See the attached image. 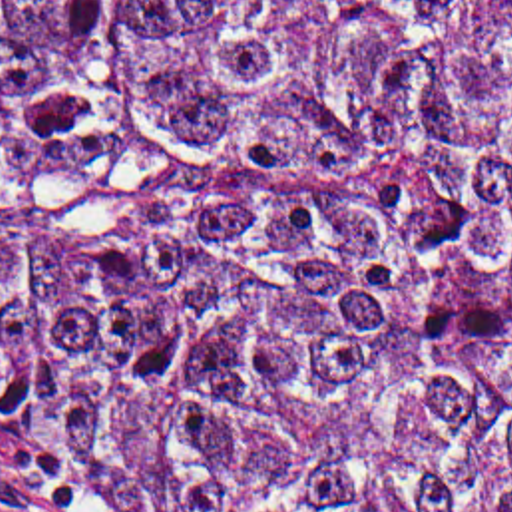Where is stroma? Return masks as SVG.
Returning a JSON list of instances; mask_svg holds the SVG:
<instances>
[{
	"label": "stroma",
	"mask_w": 512,
	"mask_h": 512,
	"mask_svg": "<svg viewBox=\"0 0 512 512\" xmlns=\"http://www.w3.org/2000/svg\"><path fill=\"white\" fill-rule=\"evenodd\" d=\"M0 512H133L115 486L93 468L0 466Z\"/></svg>",
	"instance_id": "stroma-1"
}]
</instances>
